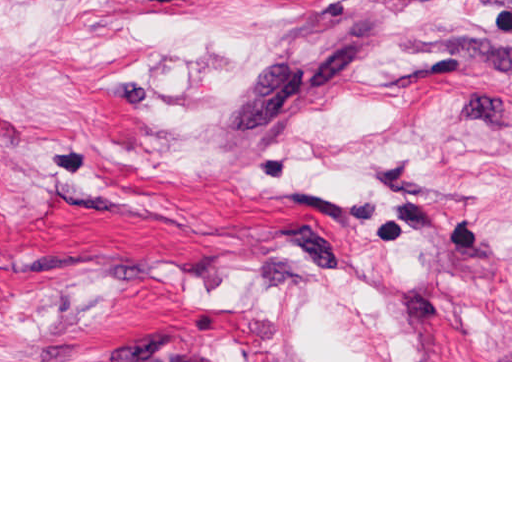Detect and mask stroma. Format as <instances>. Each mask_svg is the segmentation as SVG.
Returning a JSON list of instances; mask_svg holds the SVG:
<instances>
[{
	"label": "stroma",
	"mask_w": 512,
	"mask_h": 512,
	"mask_svg": "<svg viewBox=\"0 0 512 512\" xmlns=\"http://www.w3.org/2000/svg\"><path fill=\"white\" fill-rule=\"evenodd\" d=\"M0 362H512V0H0Z\"/></svg>",
	"instance_id": "stroma-1"
}]
</instances>
